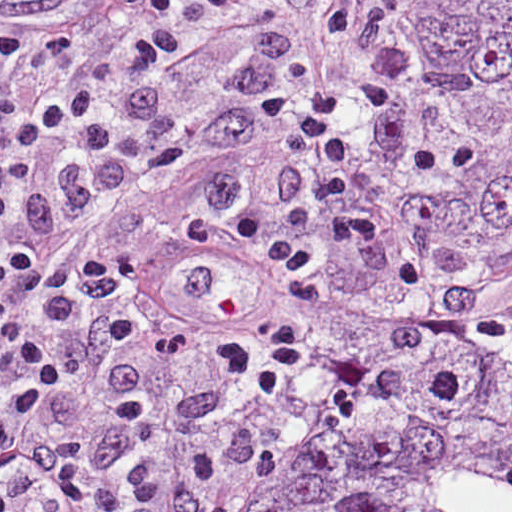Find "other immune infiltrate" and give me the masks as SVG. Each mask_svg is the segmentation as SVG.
<instances>
[{"instance_id":"bc1004c8","label":"other immune infiltrate","mask_w":512,"mask_h":512,"mask_svg":"<svg viewBox=\"0 0 512 512\" xmlns=\"http://www.w3.org/2000/svg\"><path fill=\"white\" fill-rule=\"evenodd\" d=\"M141 5L149 27L156 30H225L249 13L215 18L207 0H141Z\"/></svg>"}]
</instances>
